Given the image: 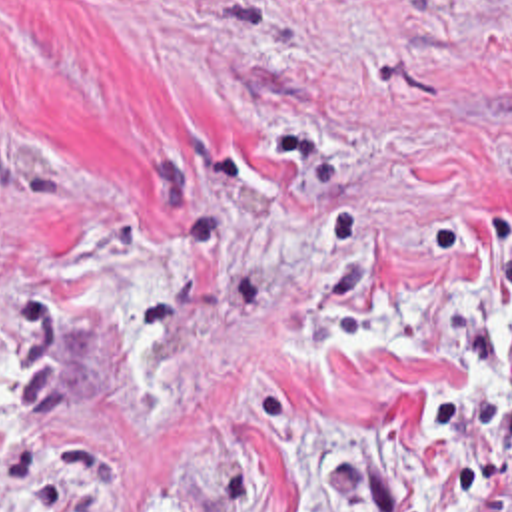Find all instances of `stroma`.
<instances>
[{
  "mask_svg": "<svg viewBox=\"0 0 512 512\" xmlns=\"http://www.w3.org/2000/svg\"><path fill=\"white\" fill-rule=\"evenodd\" d=\"M496 244L512 0H0V512H424Z\"/></svg>",
  "mask_w": 512,
  "mask_h": 512,
  "instance_id": "stroma-1",
  "label": "stroma"
}]
</instances>
